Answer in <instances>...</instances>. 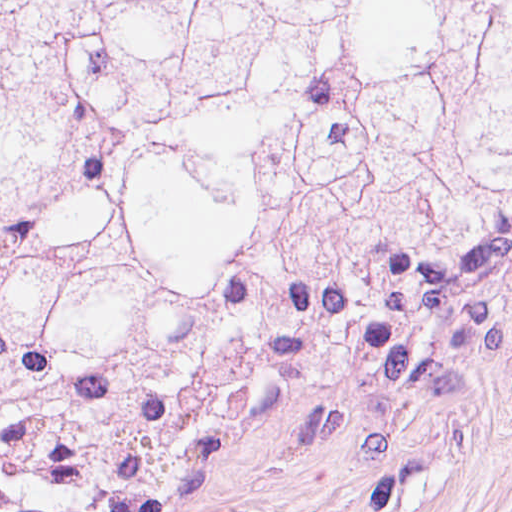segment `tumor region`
Returning <instances> with one entry per match:
<instances>
[{
  "mask_svg": "<svg viewBox=\"0 0 512 512\" xmlns=\"http://www.w3.org/2000/svg\"><path fill=\"white\" fill-rule=\"evenodd\" d=\"M512 210V0H1V482Z\"/></svg>",
  "mask_w": 512,
  "mask_h": 512,
  "instance_id": "tumor-region-1",
  "label": "tumor region"
}]
</instances>
